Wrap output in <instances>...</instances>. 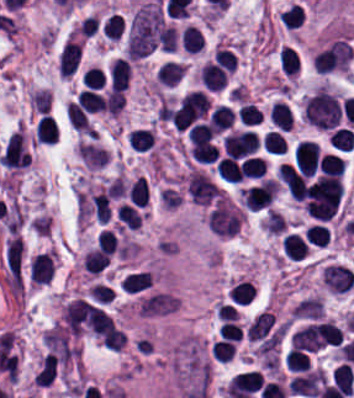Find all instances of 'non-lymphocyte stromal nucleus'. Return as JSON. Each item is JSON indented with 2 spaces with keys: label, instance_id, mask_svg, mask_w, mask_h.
<instances>
[{
  "label": "non-lymphocyte stromal nucleus",
  "instance_id": "1",
  "mask_svg": "<svg viewBox=\"0 0 354 398\" xmlns=\"http://www.w3.org/2000/svg\"><path fill=\"white\" fill-rule=\"evenodd\" d=\"M163 24L160 6L156 1L145 0L140 3L128 20L124 55L143 56L157 46Z\"/></svg>",
  "mask_w": 354,
  "mask_h": 398
},
{
  "label": "non-lymphocyte stromal nucleus",
  "instance_id": "2",
  "mask_svg": "<svg viewBox=\"0 0 354 398\" xmlns=\"http://www.w3.org/2000/svg\"><path fill=\"white\" fill-rule=\"evenodd\" d=\"M340 113L338 100L324 86H317L302 105V116L317 128L336 126Z\"/></svg>",
  "mask_w": 354,
  "mask_h": 398
},
{
  "label": "non-lymphocyte stromal nucleus",
  "instance_id": "3",
  "mask_svg": "<svg viewBox=\"0 0 354 398\" xmlns=\"http://www.w3.org/2000/svg\"><path fill=\"white\" fill-rule=\"evenodd\" d=\"M22 261L21 237L11 235L6 241L5 265L8 274L19 279Z\"/></svg>",
  "mask_w": 354,
  "mask_h": 398
}]
</instances>
